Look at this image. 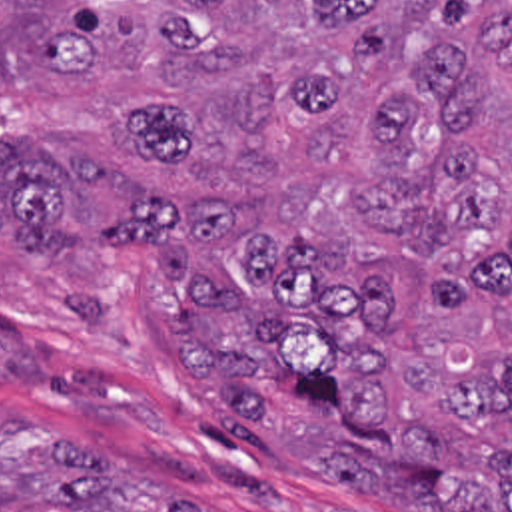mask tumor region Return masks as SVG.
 Here are the masks:
<instances>
[{"instance_id":"obj_1","label":"tumor region","mask_w":512,"mask_h":512,"mask_svg":"<svg viewBox=\"0 0 512 512\" xmlns=\"http://www.w3.org/2000/svg\"><path fill=\"white\" fill-rule=\"evenodd\" d=\"M0 251H143L220 422L390 512H512V0H0ZM0 512H208L0 418Z\"/></svg>"}]
</instances>
